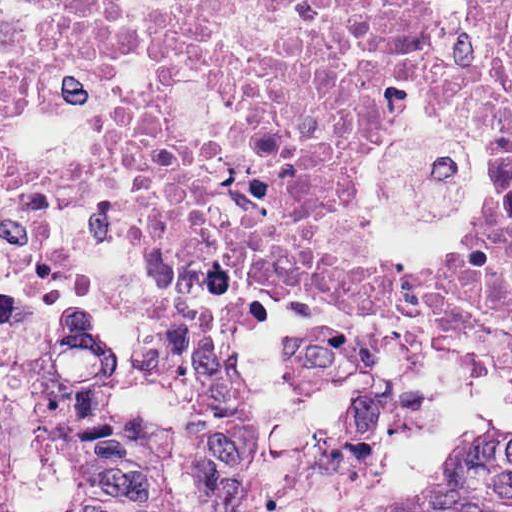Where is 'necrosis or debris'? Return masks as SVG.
<instances>
[{"instance_id": "obj_1", "label": "necrosis or debris", "mask_w": 512, "mask_h": 512, "mask_svg": "<svg viewBox=\"0 0 512 512\" xmlns=\"http://www.w3.org/2000/svg\"><path fill=\"white\" fill-rule=\"evenodd\" d=\"M409 72L481 128L467 252L512 232V0H0V288L97 220L292 331L402 280L361 182Z\"/></svg>"}]
</instances>
